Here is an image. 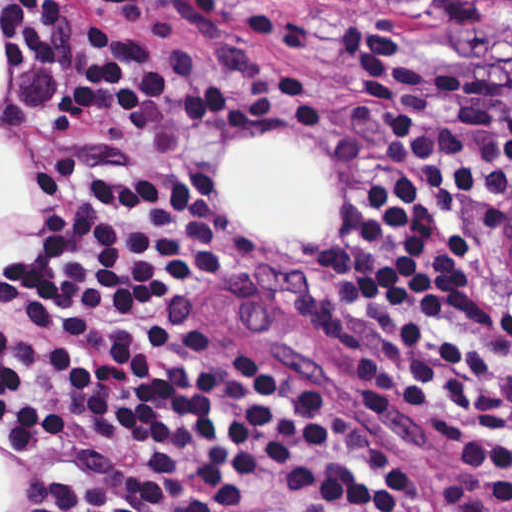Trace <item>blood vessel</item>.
<instances>
[{
    "label": "blood vessel",
    "instance_id": "obj_1",
    "mask_svg": "<svg viewBox=\"0 0 512 512\" xmlns=\"http://www.w3.org/2000/svg\"><path fill=\"white\" fill-rule=\"evenodd\" d=\"M503 232L505 238V259L512 277V214L508 215Z\"/></svg>",
    "mask_w": 512,
    "mask_h": 512
}]
</instances>
